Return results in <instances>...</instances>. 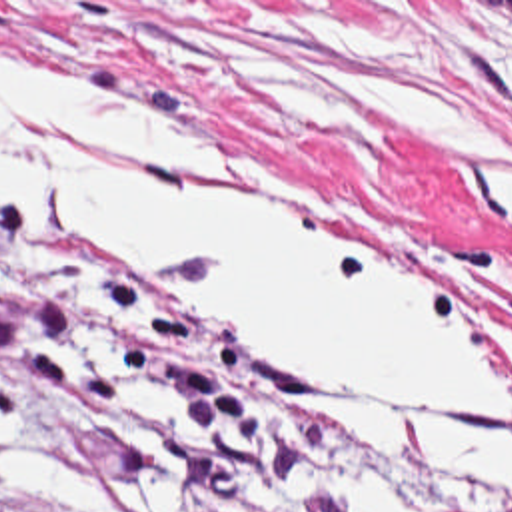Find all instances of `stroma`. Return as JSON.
Listing matches in <instances>:
<instances>
[{
    "mask_svg": "<svg viewBox=\"0 0 512 512\" xmlns=\"http://www.w3.org/2000/svg\"><path fill=\"white\" fill-rule=\"evenodd\" d=\"M0 36L74 64L240 166L192 178L336 210L438 303L512 343V224L470 148L512 134L464 72L512 64V0H0ZM0 401L116 512H330L306 463L352 461L424 512H508L378 427H348L282 341L242 337L128 260L0 204ZM0 512H78L0 485Z\"/></svg>",
    "mask_w": 512,
    "mask_h": 512,
    "instance_id": "stroma-1",
    "label": "stroma"
}]
</instances>
